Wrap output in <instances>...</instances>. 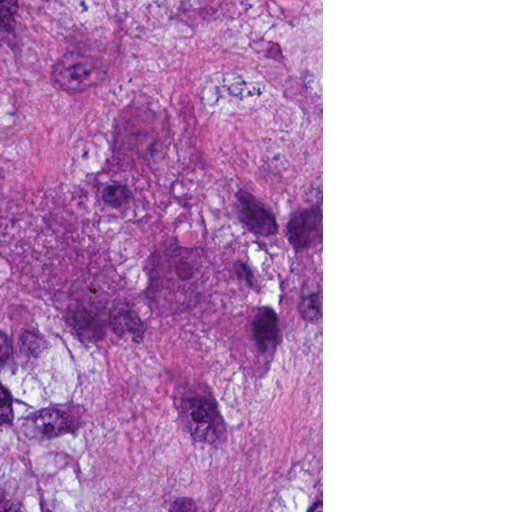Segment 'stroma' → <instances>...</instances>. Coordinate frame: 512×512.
Masks as SVG:
<instances>
[{
  "mask_svg": "<svg viewBox=\"0 0 512 512\" xmlns=\"http://www.w3.org/2000/svg\"><path fill=\"white\" fill-rule=\"evenodd\" d=\"M161 512H323V0H161Z\"/></svg>",
  "mask_w": 512,
  "mask_h": 512,
  "instance_id": "obj_1",
  "label": "stroma"
}]
</instances>
